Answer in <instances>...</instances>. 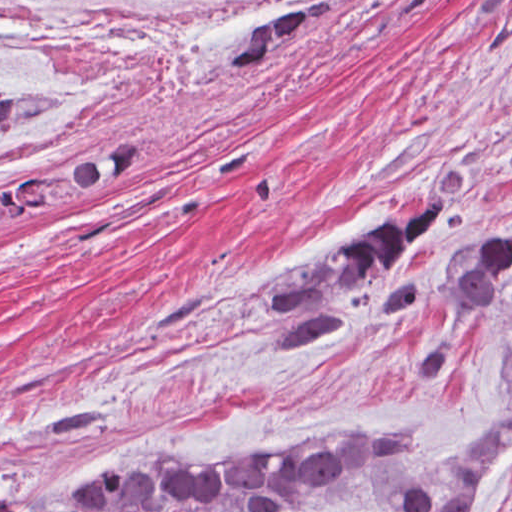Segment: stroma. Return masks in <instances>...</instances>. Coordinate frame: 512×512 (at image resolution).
<instances>
[{"instance_id":"stroma-1","label":"stroma","mask_w":512,"mask_h":512,"mask_svg":"<svg viewBox=\"0 0 512 512\" xmlns=\"http://www.w3.org/2000/svg\"><path fill=\"white\" fill-rule=\"evenodd\" d=\"M248 35L142 85L49 94L53 110L0 129H40L56 162L137 144L102 190L0 211V512H71L118 457L346 427L446 450L502 414L512 286L460 313L446 282L472 232L512 221V0H335L269 71L232 75ZM429 191L449 210L328 304L347 325L275 353L274 284ZM476 512H512V443Z\"/></svg>"}]
</instances>
